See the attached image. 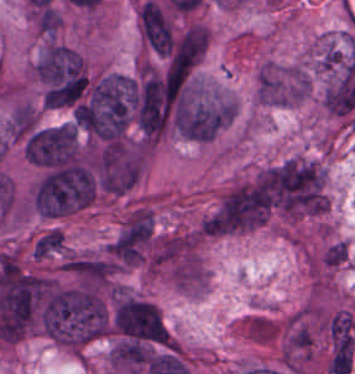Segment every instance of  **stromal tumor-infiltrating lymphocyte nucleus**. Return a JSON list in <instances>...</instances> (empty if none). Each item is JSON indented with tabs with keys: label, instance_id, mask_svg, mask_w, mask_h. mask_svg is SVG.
Wrapping results in <instances>:
<instances>
[{
	"label": "stromal tumor-infiltrating lymphocyte nucleus",
	"instance_id": "1",
	"mask_svg": "<svg viewBox=\"0 0 355 374\" xmlns=\"http://www.w3.org/2000/svg\"><path fill=\"white\" fill-rule=\"evenodd\" d=\"M208 42L207 28L200 23H192L174 45L169 63H194Z\"/></svg>",
	"mask_w": 355,
	"mask_h": 374
}]
</instances>
